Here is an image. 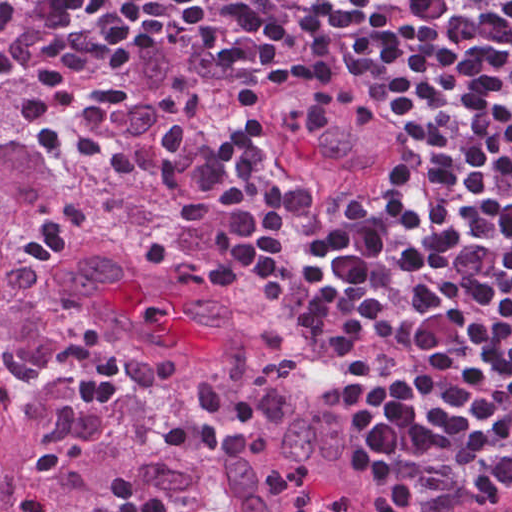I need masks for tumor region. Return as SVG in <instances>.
Returning a JSON list of instances; mask_svg holds the SVG:
<instances>
[{"label": "tumor region", "mask_w": 512, "mask_h": 512, "mask_svg": "<svg viewBox=\"0 0 512 512\" xmlns=\"http://www.w3.org/2000/svg\"><path fill=\"white\" fill-rule=\"evenodd\" d=\"M70 29L54 0H0V512L33 488L61 512H106L117 471L215 512H399L203 190L207 46L141 39L110 83L118 144L34 200L39 158L5 133ZM285 70L249 128L323 202L349 204L399 159L383 90L356 59ZM175 417L253 450L175 453L160 441Z\"/></svg>", "instance_id": "1"}]
</instances>
